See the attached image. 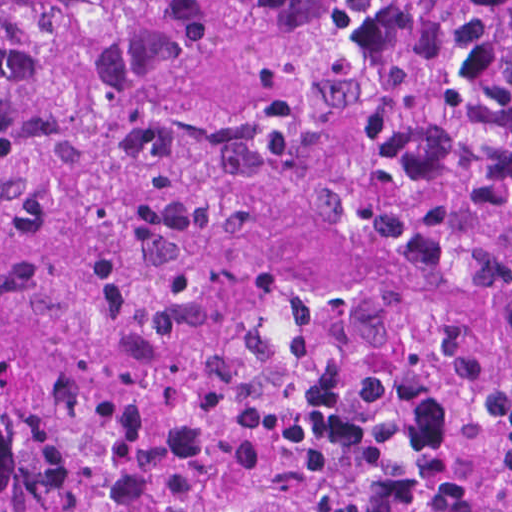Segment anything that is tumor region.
I'll use <instances>...</instances> for the list:
<instances>
[{
    "mask_svg": "<svg viewBox=\"0 0 512 512\" xmlns=\"http://www.w3.org/2000/svg\"><path fill=\"white\" fill-rule=\"evenodd\" d=\"M0 512H512V0H0Z\"/></svg>",
    "mask_w": 512,
    "mask_h": 512,
    "instance_id": "1",
    "label": "tumor region"
}]
</instances>
